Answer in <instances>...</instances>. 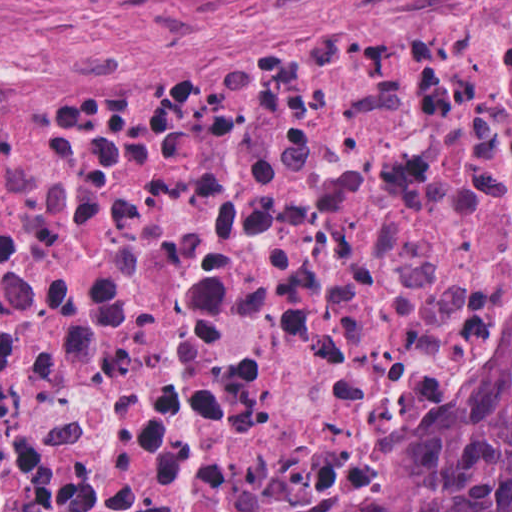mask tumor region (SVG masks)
Instances as JSON below:
<instances>
[{"label":"tumor region","instance_id":"e687c5a6","mask_svg":"<svg viewBox=\"0 0 512 512\" xmlns=\"http://www.w3.org/2000/svg\"><path fill=\"white\" fill-rule=\"evenodd\" d=\"M498 406L463 458L382 512H512V314L496 336Z\"/></svg>","mask_w":512,"mask_h":512}]
</instances>
